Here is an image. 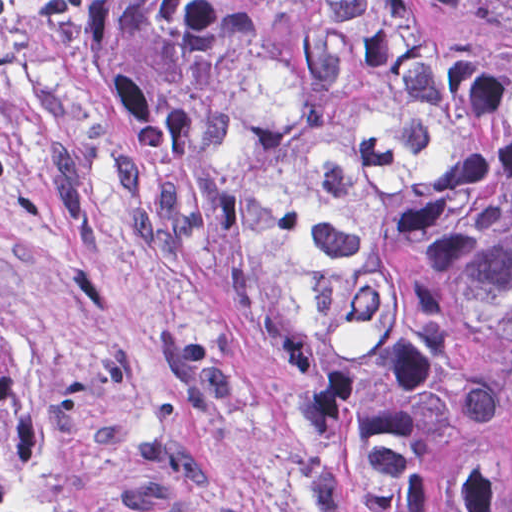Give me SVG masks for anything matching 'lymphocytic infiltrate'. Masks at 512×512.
Instances as JSON below:
<instances>
[{
  "instance_id": "obj_1",
  "label": "lymphocytic infiltrate",
  "mask_w": 512,
  "mask_h": 512,
  "mask_svg": "<svg viewBox=\"0 0 512 512\" xmlns=\"http://www.w3.org/2000/svg\"><path fill=\"white\" fill-rule=\"evenodd\" d=\"M79 0H0L1 33H52L69 20Z\"/></svg>"
}]
</instances>
